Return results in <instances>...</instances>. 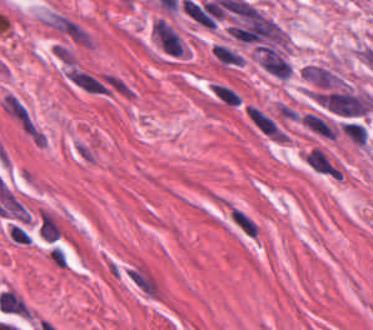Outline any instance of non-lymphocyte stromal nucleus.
Returning <instances> with one entry per match:
<instances>
[{
    "label": "non-lymphocyte stromal nucleus",
    "instance_id": "obj_1",
    "mask_svg": "<svg viewBox=\"0 0 373 330\" xmlns=\"http://www.w3.org/2000/svg\"><path fill=\"white\" fill-rule=\"evenodd\" d=\"M2 110L31 143H44V131L25 101L15 92L5 91Z\"/></svg>",
    "mask_w": 373,
    "mask_h": 330
},
{
    "label": "non-lymphocyte stromal nucleus",
    "instance_id": "obj_2",
    "mask_svg": "<svg viewBox=\"0 0 373 330\" xmlns=\"http://www.w3.org/2000/svg\"><path fill=\"white\" fill-rule=\"evenodd\" d=\"M302 157L305 163L316 171L339 180L341 172L318 148H313L309 152L302 155Z\"/></svg>",
    "mask_w": 373,
    "mask_h": 330
},
{
    "label": "non-lymphocyte stromal nucleus",
    "instance_id": "obj_3",
    "mask_svg": "<svg viewBox=\"0 0 373 330\" xmlns=\"http://www.w3.org/2000/svg\"><path fill=\"white\" fill-rule=\"evenodd\" d=\"M38 233L41 240L54 241L60 237V231L53 219L48 213L40 210Z\"/></svg>",
    "mask_w": 373,
    "mask_h": 330
},
{
    "label": "non-lymphocyte stromal nucleus",
    "instance_id": "obj_4",
    "mask_svg": "<svg viewBox=\"0 0 373 330\" xmlns=\"http://www.w3.org/2000/svg\"><path fill=\"white\" fill-rule=\"evenodd\" d=\"M214 56L221 61L223 64L241 65L243 64V58L235 51L226 48L222 45H214L213 47Z\"/></svg>",
    "mask_w": 373,
    "mask_h": 330
}]
</instances>
